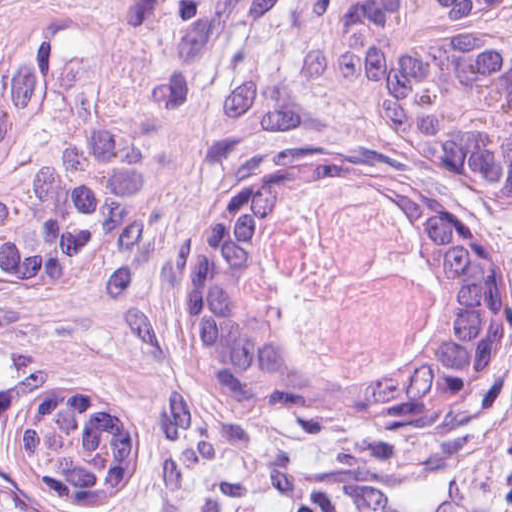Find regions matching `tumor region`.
Wrapping results in <instances>:
<instances>
[{"label":"tumor region","instance_id":"1","mask_svg":"<svg viewBox=\"0 0 512 512\" xmlns=\"http://www.w3.org/2000/svg\"><path fill=\"white\" fill-rule=\"evenodd\" d=\"M424 229L453 351L396 393L298 377L246 300L301 197ZM512 38L497 0H71L0 55V512H99L186 387L237 382L389 444L512 374Z\"/></svg>","mask_w":512,"mask_h":512}]
</instances>
